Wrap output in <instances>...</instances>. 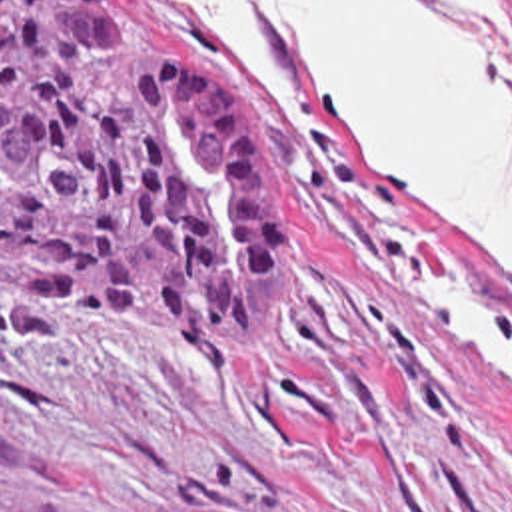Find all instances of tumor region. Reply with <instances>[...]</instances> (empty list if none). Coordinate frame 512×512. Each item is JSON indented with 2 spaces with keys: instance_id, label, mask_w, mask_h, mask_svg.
<instances>
[{
  "instance_id": "obj_1",
  "label": "tumor region",
  "mask_w": 512,
  "mask_h": 512,
  "mask_svg": "<svg viewBox=\"0 0 512 512\" xmlns=\"http://www.w3.org/2000/svg\"><path fill=\"white\" fill-rule=\"evenodd\" d=\"M0 296L224 358L278 314L276 210L238 104L146 42L118 0H0Z\"/></svg>"
}]
</instances>
